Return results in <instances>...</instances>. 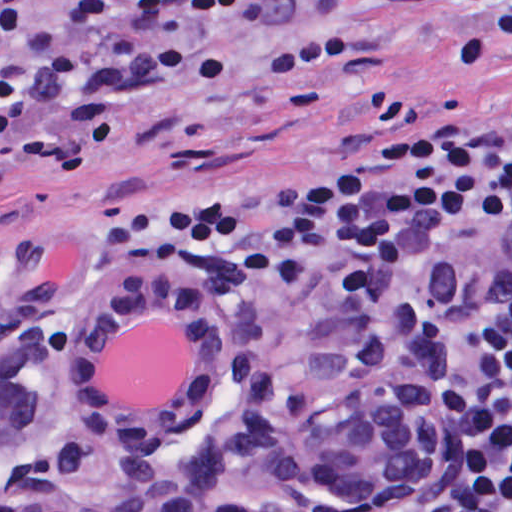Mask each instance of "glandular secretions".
<instances>
[{"instance_id":"1","label":"glandular secretions","mask_w":512,"mask_h":512,"mask_svg":"<svg viewBox=\"0 0 512 512\" xmlns=\"http://www.w3.org/2000/svg\"><path fill=\"white\" fill-rule=\"evenodd\" d=\"M192 373V339L161 316L137 320L114 336L99 384L117 405L168 406Z\"/></svg>"}]
</instances>
